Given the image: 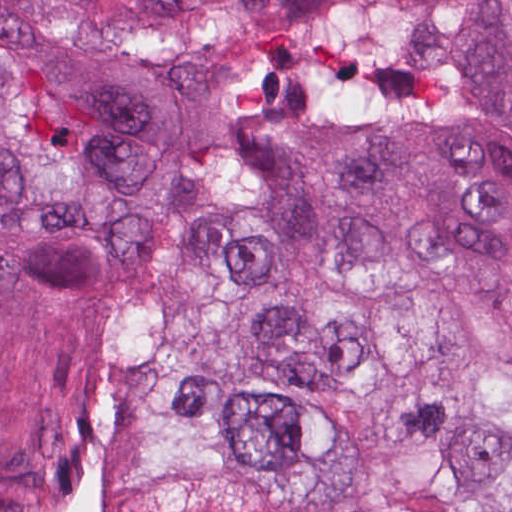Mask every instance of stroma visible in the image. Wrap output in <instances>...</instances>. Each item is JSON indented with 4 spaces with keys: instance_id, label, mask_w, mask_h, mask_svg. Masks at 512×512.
<instances>
[{
    "instance_id": "obj_1",
    "label": "stroma",
    "mask_w": 512,
    "mask_h": 512,
    "mask_svg": "<svg viewBox=\"0 0 512 512\" xmlns=\"http://www.w3.org/2000/svg\"><path fill=\"white\" fill-rule=\"evenodd\" d=\"M207 131L214 141V171L197 199L189 205L179 225L160 241H131L90 222L77 224L115 251L138 283L157 266L167 247L184 235L194 215L211 195L220 174V191L233 159L246 136L285 123H312L329 115H186ZM27 159L19 143L1 122L0 89V245L66 228L61 222H44L29 216L23 207V178Z\"/></svg>"
}]
</instances>
